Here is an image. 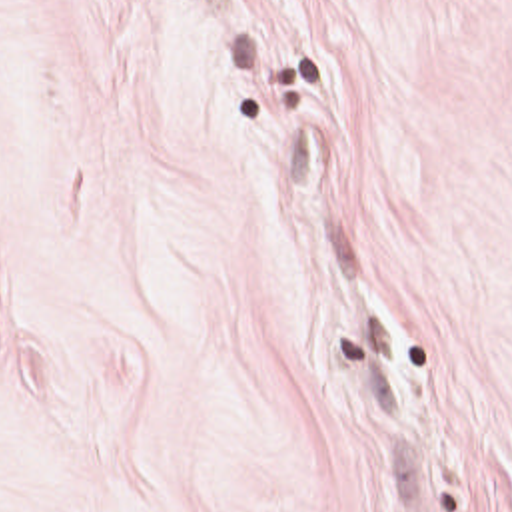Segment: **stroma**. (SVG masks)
<instances>
[{
    "label": "stroma",
    "instance_id": "35a3bbf8",
    "mask_svg": "<svg viewBox=\"0 0 512 512\" xmlns=\"http://www.w3.org/2000/svg\"><path fill=\"white\" fill-rule=\"evenodd\" d=\"M0 512H512V0H0Z\"/></svg>",
    "mask_w": 512,
    "mask_h": 512
}]
</instances>
